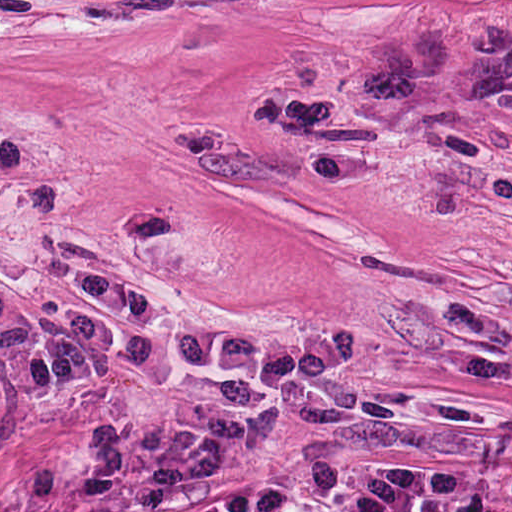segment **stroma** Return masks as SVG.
I'll return each mask as SVG.
<instances>
[{"instance_id":"stroma-1","label":"stroma","mask_w":512,"mask_h":512,"mask_svg":"<svg viewBox=\"0 0 512 512\" xmlns=\"http://www.w3.org/2000/svg\"><path fill=\"white\" fill-rule=\"evenodd\" d=\"M512 0H50L0 157L512 323V105L376 70Z\"/></svg>"}]
</instances>
